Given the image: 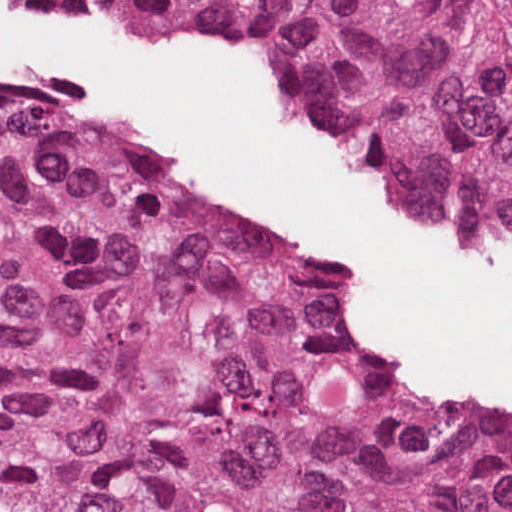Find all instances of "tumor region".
<instances>
[{
  "label": "tumor region",
  "mask_w": 512,
  "mask_h": 512,
  "mask_svg": "<svg viewBox=\"0 0 512 512\" xmlns=\"http://www.w3.org/2000/svg\"><path fill=\"white\" fill-rule=\"evenodd\" d=\"M312 286L0 88V512H512V426L357 374Z\"/></svg>",
  "instance_id": "tumor-region-1"
}]
</instances>
